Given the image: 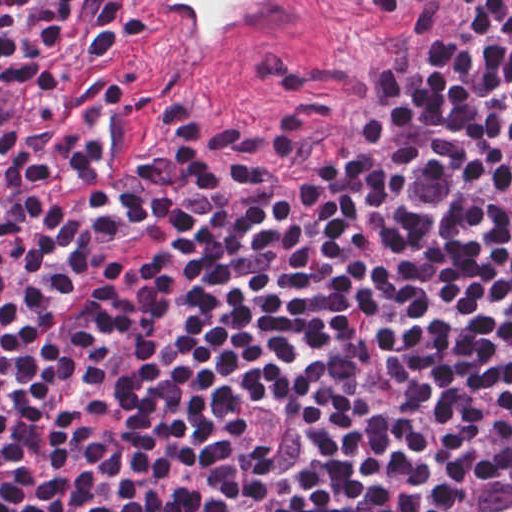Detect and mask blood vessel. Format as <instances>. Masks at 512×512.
<instances>
[{"label":"blood vessel","instance_id":"1","mask_svg":"<svg viewBox=\"0 0 512 512\" xmlns=\"http://www.w3.org/2000/svg\"><path fill=\"white\" fill-rule=\"evenodd\" d=\"M160 57L220 84L287 77L336 42L345 0H105Z\"/></svg>","mask_w":512,"mask_h":512}]
</instances>
